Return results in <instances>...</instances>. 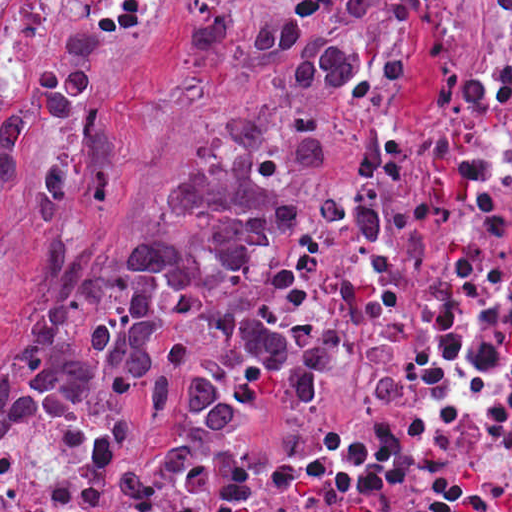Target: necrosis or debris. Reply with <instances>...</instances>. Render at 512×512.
<instances>
[{"mask_svg":"<svg viewBox=\"0 0 512 512\" xmlns=\"http://www.w3.org/2000/svg\"><path fill=\"white\" fill-rule=\"evenodd\" d=\"M235 275L333 366L326 408L154 438L34 391L0 421V512H512V144Z\"/></svg>","mask_w":512,"mask_h":512,"instance_id":"4bbe7bcc","label":"necrosis or debris"}]
</instances>
